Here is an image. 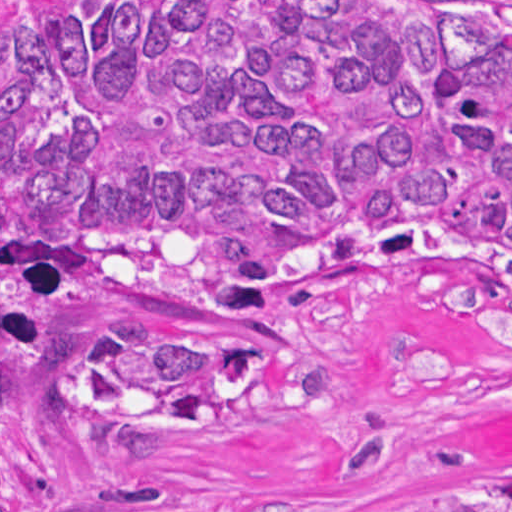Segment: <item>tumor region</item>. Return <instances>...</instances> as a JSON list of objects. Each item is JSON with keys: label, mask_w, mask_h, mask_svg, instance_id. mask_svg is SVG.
<instances>
[{"label": "tumor region", "mask_w": 512, "mask_h": 512, "mask_svg": "<svg viewBox=\"0 0 512 512\" xmlns=\"http://www.w3.org/2000/svg\"><path fill=\"white\" fill-rule=\"evenodd\" d=\"M340 292L512 352V0H1V492L239 409Z\"/></svg>", "instance_id": "1"}]
</instances>
